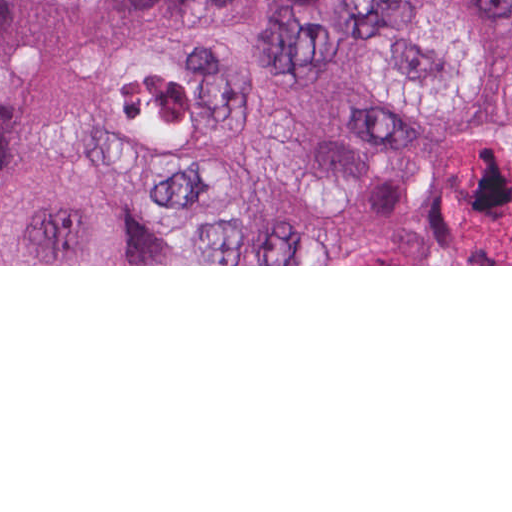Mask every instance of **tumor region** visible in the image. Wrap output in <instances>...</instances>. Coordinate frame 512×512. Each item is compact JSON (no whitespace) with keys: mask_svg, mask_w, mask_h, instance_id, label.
<instances>
[{"mask_svg":"<svg viewBox=\"0 0 512 512\" xmlns=\"http://www.w3.org/2000/svg\"><path fill=\"white\" fill-rule=\"evenodd\" d=\"M512 264V0H0V265Z\"/></svg>","mask_w":512,"mask_h":512,"instance_id":"1","label":"tumor region"}]
</instances>
